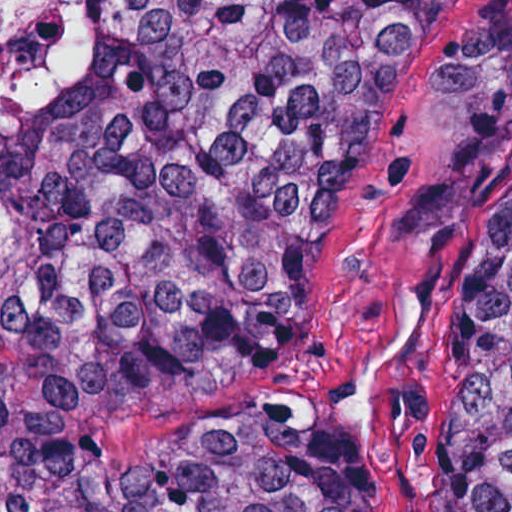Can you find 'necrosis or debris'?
<instances>
[{"label": "necrosis or debris", "mask_w": 512, "mask_h": 512, "mask_svg": "<svg viewBox=\"0 0 512 512\" xmlns=\"http://www.w3.org/2000/svg\"><path fill=\"white\" fill-rule=\"evenodd\" d=\"M98 0H0V93L20 103L64 95L96 57Z\"/></svg>", "instance_id": "obj_1"}]
</instances>
